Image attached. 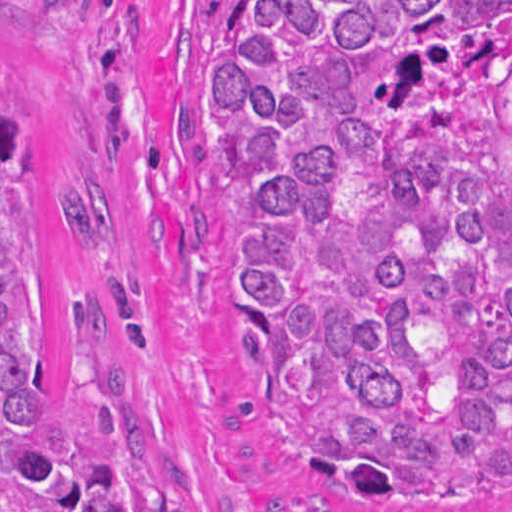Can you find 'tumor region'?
<instances>
[{
	"instance_id": "e687c5a6",
	"label": "tumor region",
	"mask_w": 512,
	"mask_h": 512,
	"mask_svg": "<svg viewBox=\"0 0 512 512\" xmlns=\"http://www.w3.org/2000/svg\"><path fill=\"white\" fill-rule=\"evenodd\" d=\"M231 358L371 511L512 507V1H210ZM37 117L0 58V512H191L94 293L46 403Z\"/></svg>"
}]
</instances>
